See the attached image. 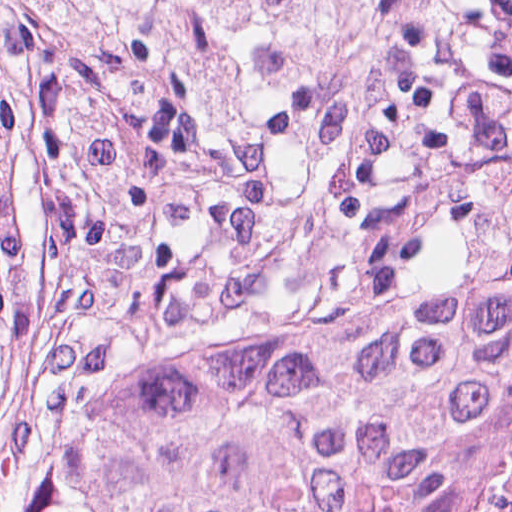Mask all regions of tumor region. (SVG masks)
<instances>
[{"instance_id": "1", "label": "tumor region", "mask_w": 512, "mask_h": 512, "mask_svg": "<svg viewBox=\"0 0 512 512\" xmlns=\"http://www.w3.org/2000/svg\"><path fill=\"white\" fill-rule=\"evenodd\" d=\"M95 57L173 64L212 125L300 57L314 0H1ZM28 285L0 177V388ZM512 372V265L327 320L184 340L107 399L33 512H431L437 443Z\"/></svg>"}]
</instances>
